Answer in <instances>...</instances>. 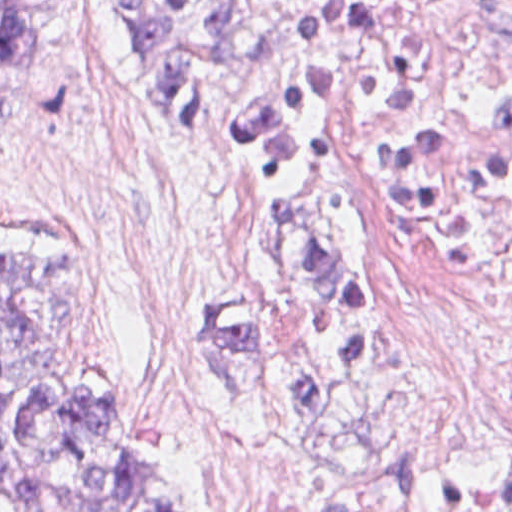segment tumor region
Segmentation results:
<instances>
[{"mask_svg":"<svg viewBox=\"0 0 512 512\" xmlns=\"http://www.w3.org/2000/svg\"><path fill=\"white\" fill-rule=\"evenodd\" d=\"M401 0H310L277 71L242 116L237 155L261 214L258 297L217 322L253 387L316 418H361L372 286L344 201L341 84ZM150 94L192 118L249 55L260 0H119ZM60 0H0V116L40 60ZM215 91L212 102L211 97ZM95 294L74 233L0 241V512H196V490L153 451L111 379L79 360ZM512 512V469L484 475Z\"/></svg>","mask_w":512,"mask_h":512,"instance_id":"e687c5a6","label":"tumor region"}]
</instances>
